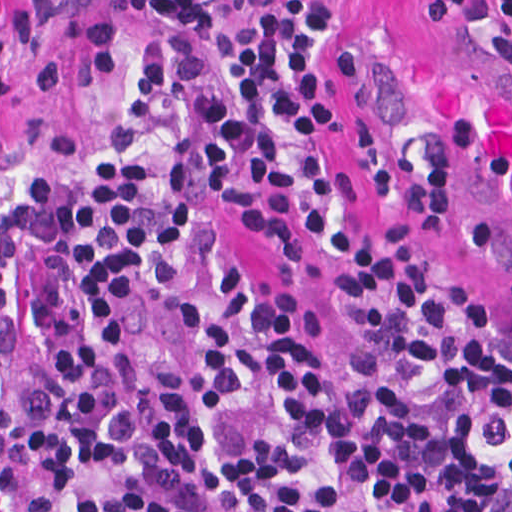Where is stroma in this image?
I'll return each instance as SVG.
<instances>
[{
  "instance_id": "35a3bbf8",
  "label": "stroma",
  "mask_w": 512,
  "mask_h": 512,
  "mask_svg": "<svg viewBox=\"0 0 512 512\" xmlns=\"http://www.w3.org/2000/svg\"><path fill=\"white\" fill-rule=\"evenodd\" d=\"M329 1L340 22L332 86L336 126L322 138L333 160L327 218L296 262L228 212L213 221L251 284L297 303L304 353L326 381L347 367L359 341L339 298L341 234L381 240L396 223L413 245L512 318V284L436 208L345 83V52L476 49L512 59V23L429 26L424 0ZM134 5L0 0V512L1 188L61 161L82 143L110 101L121 31Z\"/></svg>"
}]
</instances>
